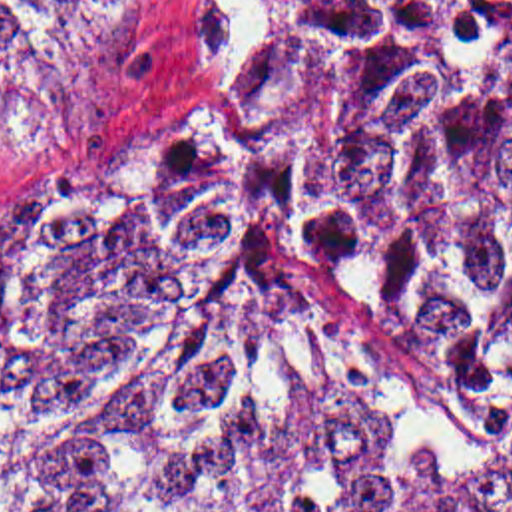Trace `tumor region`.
Instances as JSON below:
<instances>
[{"label": "tumor region", "instance_id": "1", "mask_svg": "<svg viewBox=\"0 0 512 512\" xmlns=\"http://www.w3.org/2000/svg\"><path fill=\"white\" fill-rule=\"evenodd\" d=\"M124 0H0V85ZM248 159L343 320L512 430V0H250ZM0 185V512H512L361 468L246 165L82 145Z\"/></svg>", "mask_w": 512, "mask_h": 512}]
</instances>
